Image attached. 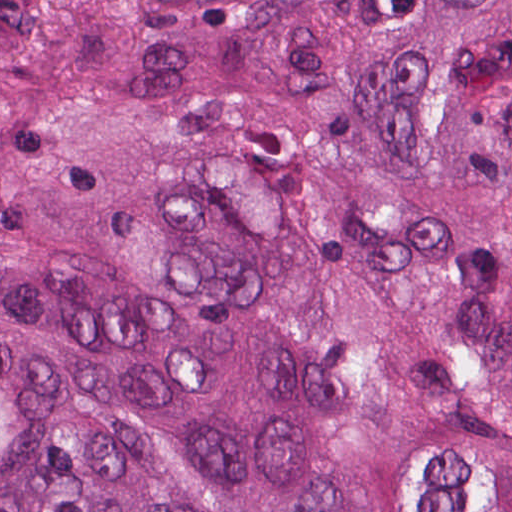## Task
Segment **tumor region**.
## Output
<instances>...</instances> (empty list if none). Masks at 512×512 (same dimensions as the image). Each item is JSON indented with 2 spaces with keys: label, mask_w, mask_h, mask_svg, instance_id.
<instances>
[{
  "label": "tumor region",
  "mask_w": 512,
  "mask_h": 512,
  "mask_svg": "<svg viewBox=\"0 0 512 512\" xmlns=\"http://www.w3.org/2000/svg\"><path fill=\"white\" fill-rule=\"evenodd\" d=\"M0 512H512V0H0Z\"/></svg>",
  "instance_id": "tumor-region-1"
}]
</instances>
